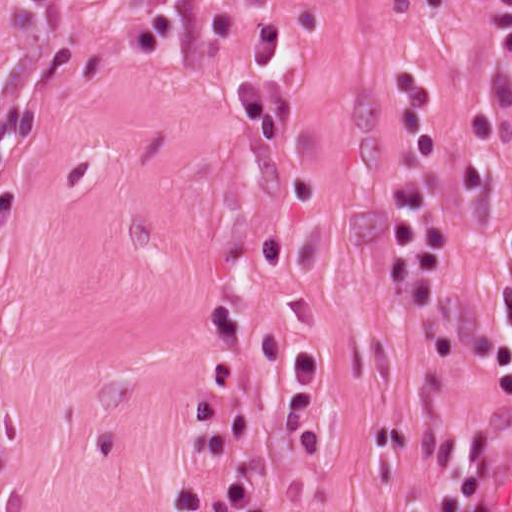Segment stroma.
I'll return each mask as SVG.
<instances>
[{
    "mask_svg": "<svg viewBox=\"0 0 512 512\" xmlns=\"http://www.w3.org/2000/svg\"><path fill=\"white\" fill-rule=\"evenodd\" d=\"M272 18L297 113L260 150L233 82ZM400 69L448 105L439 304L495 326L512 0H0V512H178L245 471L239 512H404L441 452H473L487 512L512 400L381 286ZM229 357L256 429L206 461Z\"/></svg>",
    "mask_w": 512,
    "mask_h": 512,
    "instance_id": "stroma-1",
    "label": "stroma"
}]
</instances>
